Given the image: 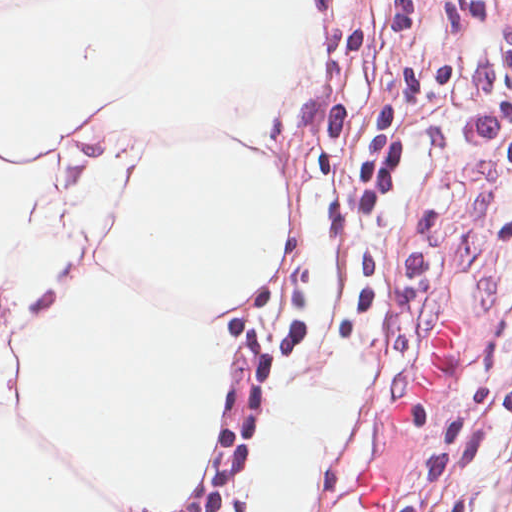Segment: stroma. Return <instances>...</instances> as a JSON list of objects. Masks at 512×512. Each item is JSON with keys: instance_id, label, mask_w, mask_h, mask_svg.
I'll use <instances>...</instances> for the list:
<instances>
[{"instance_id": "35a3bbf8", "label": "stroma", "mask_w": 512, "mask_h": 512, "mask_svg": "<svg viewBox=\"0 0 512 512\" xmlns=\"http://www.w3.org/2000/svg\"><path fill=\"white\" fill-rule=\"evenodd\" d=\"M512 287V170L493 133L484 60L409 0H387L304 391L349 368L360 413L298 512H351L363 473L390 512H512V377L498 334ZM454 305L461 366L423 422L388 418Z\"/></svg>"}]
</instances>
